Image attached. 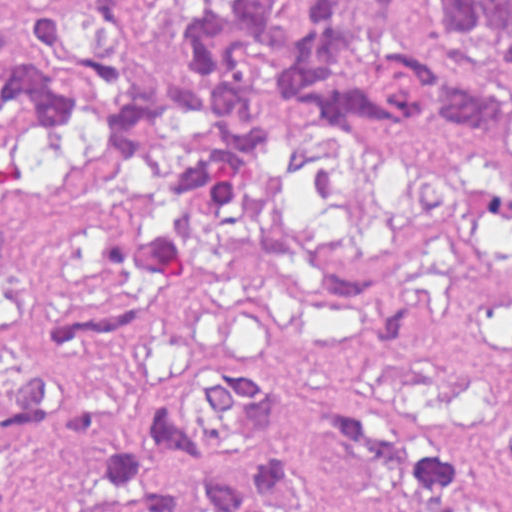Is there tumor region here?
<instances>
[{
  "instance_id": "e687c5a6",
  "label": "tumor region",
  "mask_w": 512,
  "mask_h": 512,
  "mask_svg": "<svg viewBox=\"0 0 512 512\" xmlns=\"http://www.w3.org/2000/svg\"><path fill=\"white\" fill-rule=\"evenodd\" d=\"M167 1L175 49L157 60L146 0H90L68 17L26 9V29L0 26V133L82 149L91 129L148 180L152 200L116 227L124 271L184 275L200 239L267 188L287 124L251 113L266 93H287L335 133L376 120L418 133L434 120L493 141L510 121L512 0ZM151 330L146 308L56 327L42 372L0 377V429L84 459L88 483L122 512H191L140 469L84 387ZM137 417L187 476L199 512H477L451 449L366 423L308 379L215 366L148 388ZM505 443L512 462V410Z\"/></svg>"
}]
</instances>
